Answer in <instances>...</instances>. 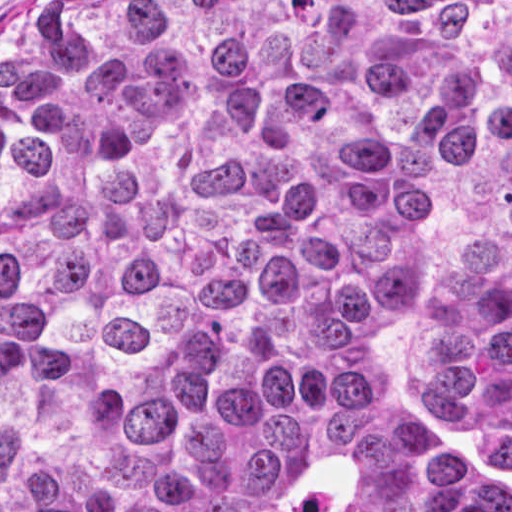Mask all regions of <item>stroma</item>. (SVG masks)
Here are the masks:
<instances>
[{
    "instance_id": "1",
    "label": "stroma",
    "mask_w": 512,
    "mask_h": 512,
    "mask_svg": "<svg viewBox=\"0 0 512 512\" xmlns=\"http://www.w3.org/2000/svg\"><path fill=\"white\" fill-rule=\"evenodd\" d=\"M61 0H0V46L15 30L33 22Z\"/></svg>"
}]
</instances>
